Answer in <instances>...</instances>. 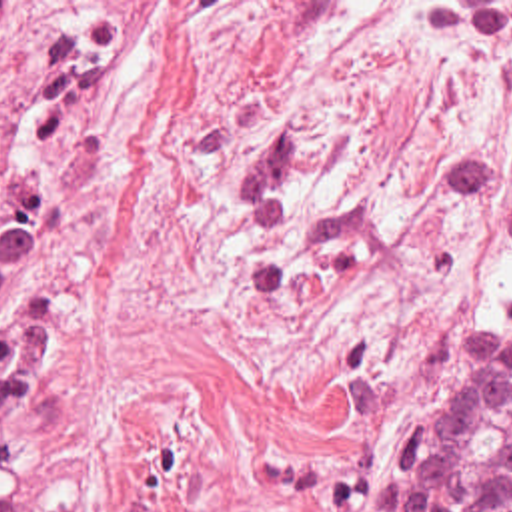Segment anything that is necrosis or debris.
<instances>
[{"label": "necrosis or debris", "instance_id": "1", "mask_svg": "<svg viewBox=\"0 0 512 512\" xmlns=\"http://www.w3.org/2000/svg\"><path fill=\"white\" fill-rule=\"evenodd\" d=\"M95 78L87 0H0V106L63 98ZM43 258V150L0 124V308Z\"/></svg>", "mask_w": 512, "mask_h": 512}]
</instances>
